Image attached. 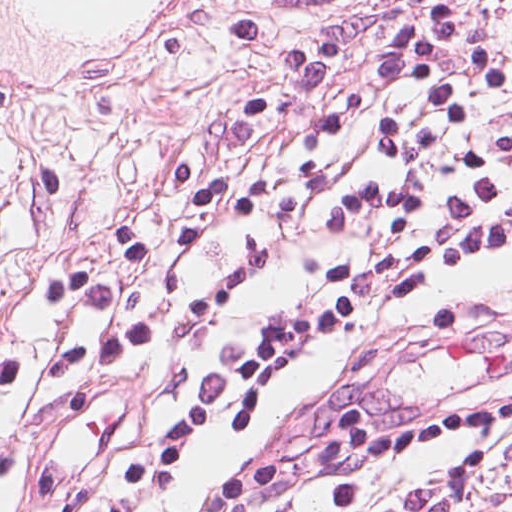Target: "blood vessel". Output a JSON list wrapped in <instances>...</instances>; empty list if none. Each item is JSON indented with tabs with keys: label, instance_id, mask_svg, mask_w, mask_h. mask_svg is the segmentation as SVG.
<instances>
[{
	"label": "blood vessel",
	"instance_id": "obj_1",
	"mask_svg": "<svg viewBox=\"0 0 512 512\" xmlns=\"http://www.w3.org/2000/svg\"><path fill=\"white\" fill-rule=\"evenodd\" d=\"M202 0H0V102L89 112L156 71Z\"/></svg>",
	"mask_w": 512,
	"mask_h": 512
}]
</instances>
